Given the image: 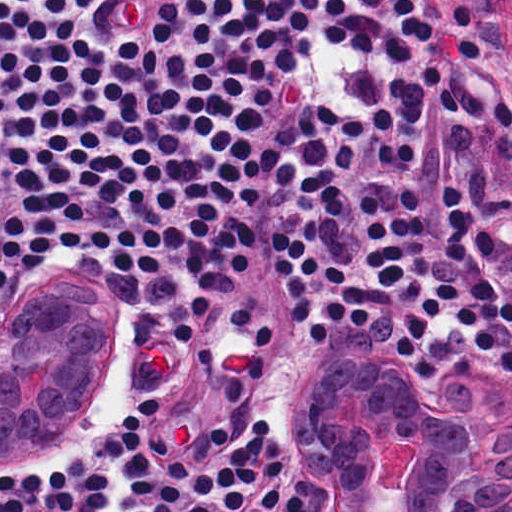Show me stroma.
I'll list each match as a JSON object with an SVG mask.
<instances>
[{
	"instance_id": "obj_1",
	"label": "stroma",
	"mask_w": 512,
	"mask_h": 512,
	"mask_svg": "<svg viewBox=\"0 0 512 512\" xmlns=\"http://www.w3.org/2000/svg\"><path fill=\"white\" fill-rule=\"evenodd\" d=\"M312 27L316 45L302 70L285 76L260 118V131L278 156L265 175L237 174L200 266L127 275L104 256L83 253L61 263L23 266L5 285L0 318L27 288L113 300L128 322V352L70 433L28 464H8L0 456V476L60 469L75 455L104 446L132 405L154 397L161 405L160 432L173 454H183L215 422L237 442L249 418L260 413L280 445V512H313L296 466L297 384L320 358L366 345L356 351L383 357L406 377L410 402L404 428L376 464L373 504L381 512H409L425 477L443 399L472 372L496 374L498 387L512 389V379L487 354L445 369L408 371L392 347L343 323L314 345L295 329L272 274L274 229L294 199L272 183L284 171L295 114L316 102L364 108L380 98L389 79H410L433 61L458 84L473 88L482 103L509 100L512 109V0H437L436 27L408 63H382L325 39L324 0H316ZM491 172L502 193L512 195V156L497 157ZM18 512L45 511L38 506ZM100 512H122L119 464L111 468L110 494ZM241 512H264L258 495ZM502 512H512V504Z\"/></svg>"
}]
</instances>
